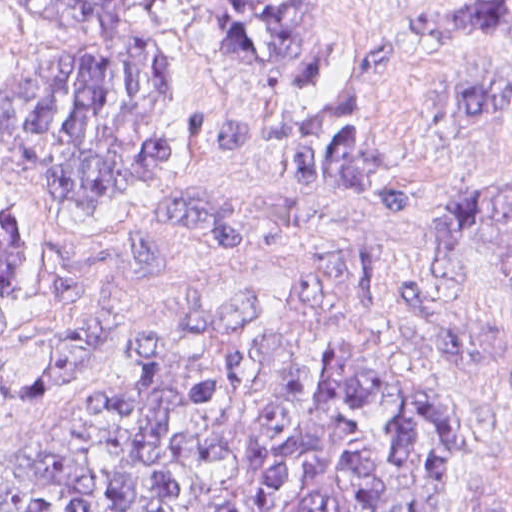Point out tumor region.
<instances>
[{"mask_svg": "<svg viewBox=\"0 0 512 512\" xmlns=\"http://www.w3.org/2000/svg\"><path fill=\"white\" fill-rule=\"evenodd\" d=\"M222 35L215 56L272 95H312L347 63L328 1H177ZM78 31L77 46L0 81V150L39 174L60 210L114 221L133 186L167 169L182 96L154 28L171 1H16ZM428 40L505 32L512 1L413 14ZM400 43L380 41L345 93L315 119L254 121L192 110L187 141L221 153L281 150L279 177L412 212L385 180L389 154L362 118ZM512 80L463 84L455 117H500ZM449 273L512 282V177L433 206ZM34 229L0 210V306L32 283ZM390 272H353L225 327L168 333L109 393L0 449V512H440L456 448L452 403L390 354L376 317ZM135 349L121 312L81 308L0 346V427L50 402L102 389ZM498 512H512V501Z\"/></svg>", "mask_w": 512, "mask_h": 512, "instance_id": "obj_1", "label": "tumor region"}]
</instances>
